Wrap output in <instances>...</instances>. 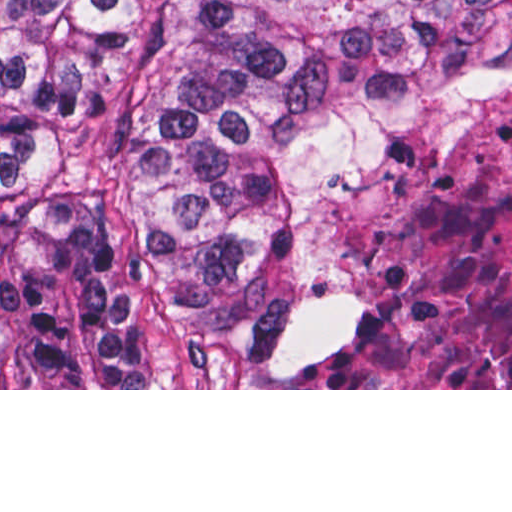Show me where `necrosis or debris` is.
Returning <instances> with one entry per match:
<instances>
[{"mask_svg":"<svg viewBox=\"0 0 512 512\" xmlns=\"http://www.w3.org/2000/svg\"><path fill=\"white\" fill-rule=\"evenodd\" d=\"M357 211L316 291L367 297V325L303 388H512V110L400 127L337 167Z\"/></svg>","mask_w":512,"mask_h":512,"instance_id":"1","label":"necrosis or debris"}]
</instances>
